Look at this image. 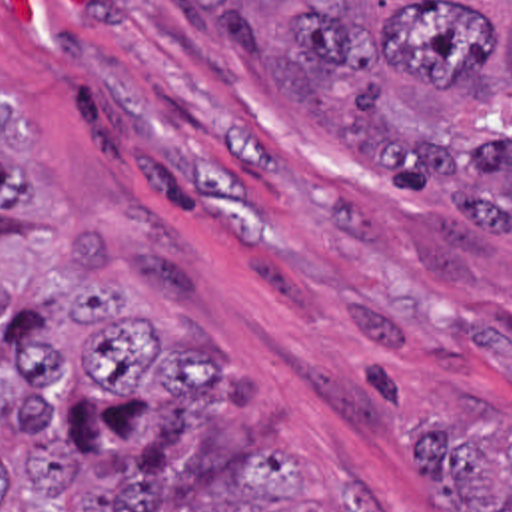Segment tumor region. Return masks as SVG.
<instances>
[{
    "label": "tumor region",
    "mask_w": 512,
    "mask_h": 512,
    "mask_svg": "<svg viewBox=\"0 0 512 512\" xmlns=\"http://www.w3.org/2000/svg\"><path fill=\"white\" fill-rule=\"evenodd\" d=\"M165 1L331 151L403 193L447 189L407 241L477 297L483 259L512 251V0ZM38 215L36 131L0 91V227ZM66 237L70 303L28 307L0 279V512H263L305 494L295 444H259L207 488L163 482L173 440L233 420L221 366L127 307L95 229ZM409 456L455 512H512L511 416L413 422Z\"/></svg>",
    "instance_id": "e687c5a6"
}]
</instances>
